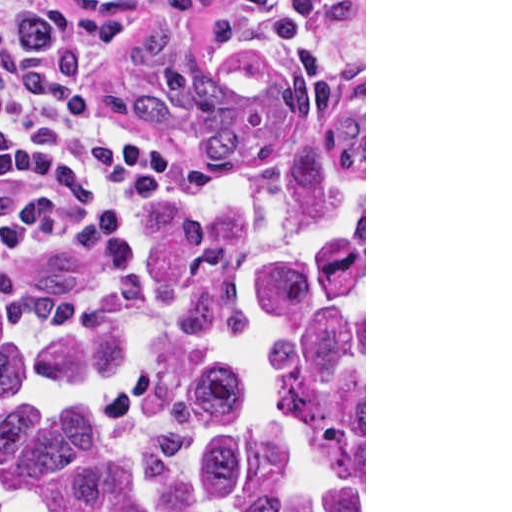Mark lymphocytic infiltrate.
<instances>
[{"instance_id":"obj_1","label":"lymphocytic infiltrate","mask_w":512,"mask_h":512,"mask_svg":"<svg viewBox=\"0 0 512 512\" xmlns=\"http://www.w3.org/2000/svg\"><path fill=\"white\" fill-rule=\"evenodd\" d=\"M262 9L272 0H223ZM116 24L71 0H0V229L106 210L186 185L179 147L111 84Z\"/></svg>"}]
</instances>
